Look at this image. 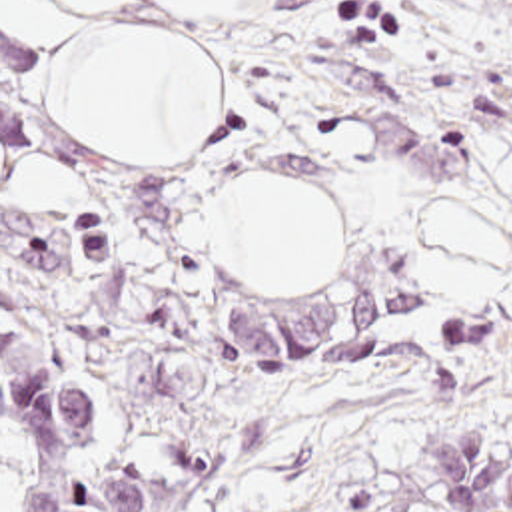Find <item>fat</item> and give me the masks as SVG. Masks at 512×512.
<instances>
[{
    "label": "fat",
    "mask_w": 512,
    "mask_h": 512,
    "mask_svg": "<svg viewBox=\"0 0 512 512\" xmlns=\"http://www.w3.org/2000/svg\"><path fill=\"white\" fill-rule=\"evenodd\" d=\"M152 1V0H136ZM188 15H214L232 0H164ZM140 47L152 157L190 153L218 123V81L196 43L142 25ZM214 251L252 281H329L341 269L337 207L297 173L240 175L212 203ZM425 267L459 303H489L505 277V233L479 197L435 199L419 213Z\"/></svg>",
    "instance_id": "53f6f03d"
}]
</instances>
